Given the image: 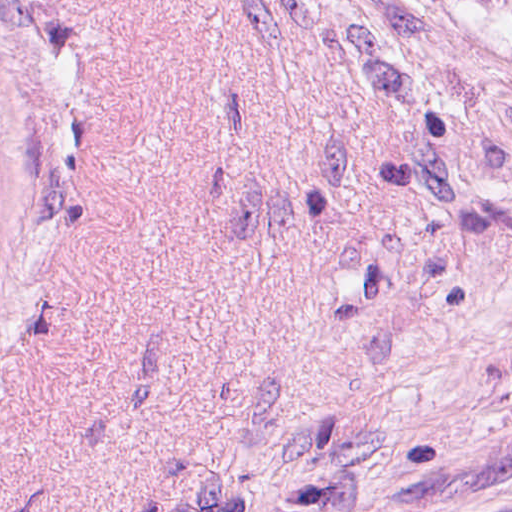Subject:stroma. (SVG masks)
I'll return each instance as SVG.
<instances>
[{
	"label": "stroma",
	"mask_w": 512,
	"mask_h": 512,
	"mask_svg": "<svg viewBox=\"0 0 512 512\" xmlns=\"http://www.w3.org/2000/svg\"><path fill=\"white\" fill-rule=\"evenodd\" d=\"M0 512H512V19L0 0Z\"/></svg>",
	"instance_id": "35a3bbf8"
}]
</instances>
